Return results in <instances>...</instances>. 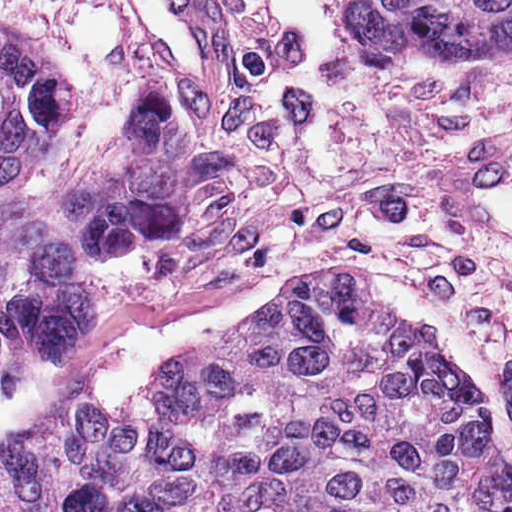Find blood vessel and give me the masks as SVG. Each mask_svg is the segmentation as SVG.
I'll return each mask as SVG.
<instances>
[{
  "mask_svg": "<svg viewBox=\"0 0 512 512\" xmlns=\"http://www.w3.org/2000/svg\"><path fill=\"white\" fill-rule=\"evenodd\" d=\"M164 75L200 93L232 91L237 76L233 0H113Z\"/></svg>",
  "mask_w": 512,
  "mask_h": 512,
  "instance_id": "8fb6f2fc",
  "label": "blood vessel"
}]
</instances>
